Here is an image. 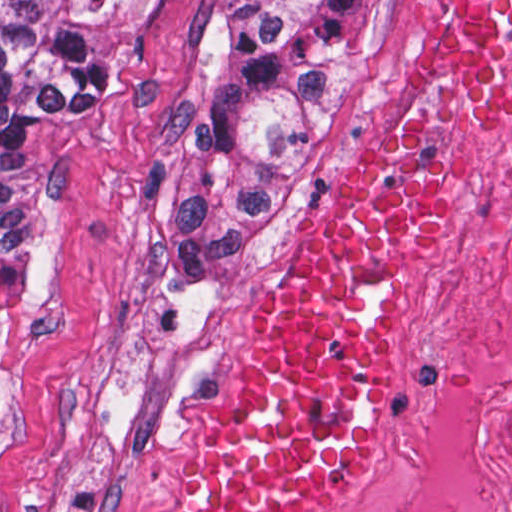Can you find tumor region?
I'll list each match as a JSON object with an SVG mask.
<instances>
[{
    "label": "tumor region",
    "instance_id": "tumor-region-1",
    "mask_svg": "<svg viewBox=\"0 0 512 512\" xmlns=\"http://www.w3.org/2000/svg\"><path fill=\"white\" fill-rule=\"evenodd\" d=\"M390 0H219L208 72L172 148L152 242L213 254L272 230L329 167ZM141 0H0V420L31 324L38 236L10 138L118 81Z\"/></svg>",
    "mask_w": 512,
    "mask_h": 512
}]
</instances>
